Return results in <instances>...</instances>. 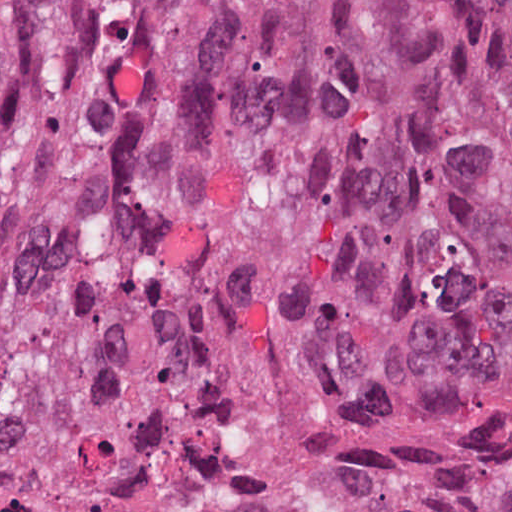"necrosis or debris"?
<instances>
[{
	"label": "necrosis or debris",
	"mask_w": 512,
	"mask_h": 512,
	"mask_svg": "<svg viewBox=\"0 0 512 512\" xmlns=\"http://www.w3.org/2000/svg\"><path fill=\"white\" fill-rule=\"evenodd\" d=\"M250 464L245 445L212 443L184 471L140 494L0 488V512H239Z\"/></svg>",
	"instance_id": "obj_1"
}]
</instances>
